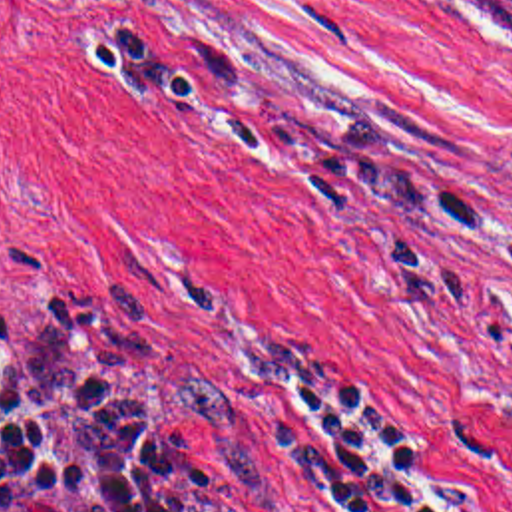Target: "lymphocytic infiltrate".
<instances>
[{"mask_svg": "<svg viewBox=\"0 0 512 512\" xmlns=\"http://www.w3.org/2000/svg\"><path fill=\"white\" fill-rule=\"evenodd\" d=\"M88 47L116 85L222 137L228 152L297 166L385 214L437 216L493 240L512 232V218L260 115L134 31H102ZM250 439L278 512H463L391 417L313 340L280 334L264 356ZM0 512H182L108 324L80 296L45 284L0 292Z\"/></svg>", "mask_w": 512, "mask_h": 512, "instance_id": "lymphocytic-infiltrate-1", "label": "lymphocytic infiltrate"}]
</instances>
